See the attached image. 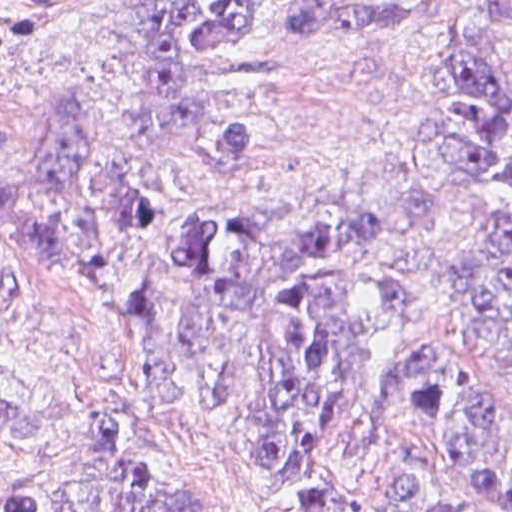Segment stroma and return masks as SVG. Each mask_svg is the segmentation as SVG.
<instances>
[{
  "mask_svg": "<svg viewBox=\"0 0 512 512\" xmlns=\"http://www.w3.org/2000/svg\"><path fill=\"white\" fill-rule=\"evenodd\" d=\"M128 1L0 0V127L30 130L53 102L81 90L99 144L129 176L203 196L219 177L206 141L234 119L246 90L226 66L206 68L197 125L179 135L155 131L126 78L124 47L103 34L104 20ZM316 1L331 0H256L254 49L271 71L264 97L273 159L256 180L260 237L250 280L211 294L160 256L162 306L202 331L201 363L224 361L230 416L204 384L143 352V321L89 291L41 282L0 305V505L28 495L70 446L101 441L257 512H287L233 423L282 388V356L263 317L268 295L308 234L381 199L392 207L387 235L350 260L378 277L424 276L415 327L444 350L450 387L481 395L497 452L512 468V364L485 330L479 298L512 204V170L491 194L494 162L512 153V136L480 163L434 248L415 209L423 185L455 196V80L441 58L462 40L486 51L512 101V35L482 23L502 0H435V14L406 34L301 51L279 21L284 10ZM26 170L0 158V179ZM475 228L447 293L446 258ZM21 239L0 221V259ZM317 444V512H421L400 491L402 469L430 489H452L454 472L396 413L337 425Z\"/></svg>",
  "mask_w": 512,
  "mask_h": 512,
  "instance_id": "35a3bbf8",
  "label": "stroma"
}]
</instances>
